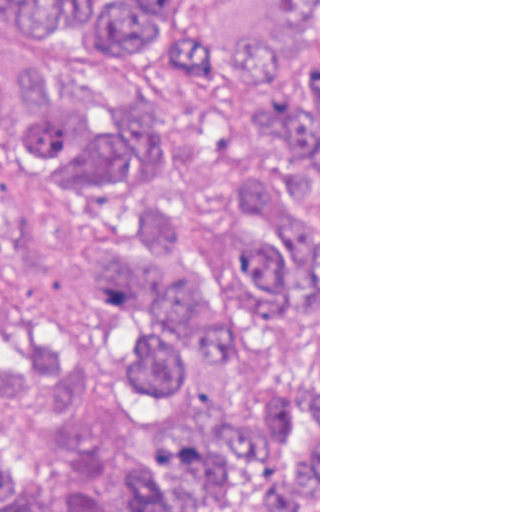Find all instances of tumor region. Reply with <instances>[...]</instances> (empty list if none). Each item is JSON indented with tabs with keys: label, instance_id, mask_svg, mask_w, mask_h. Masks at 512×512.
I'll return each mask as SVG.
<instances>
[{
	"label": "tumor region",
	"instance_id": "1",
	"mask_svg": "<svg viewBox=\"0 0 512 512\" xmlns=\"http://www.w3.org/2000/svg\"><path fill=\"white\" fill-rule=\"evenodd\" d=\"M190 1L0 0V152L70 200L144 192L175 132L16 26L94 67L179 61L209 142L208 183L86 249L115 330L0 328V512H318V0H268L238 47ZM15 266L0 222V311Z\"/></svg>",
	"mask_w": 512,
	"mask_h": 512
}]
</instances>
